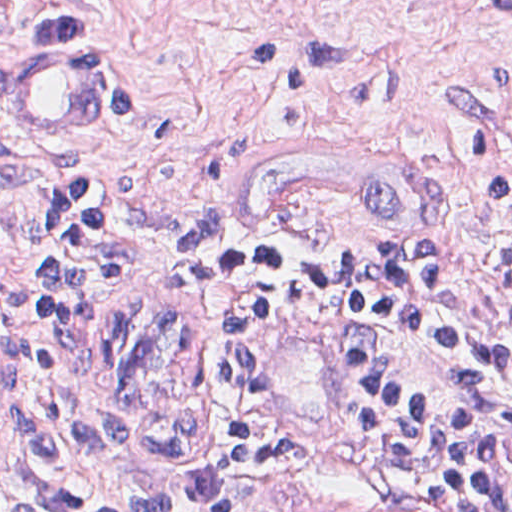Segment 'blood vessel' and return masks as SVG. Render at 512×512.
Masks as SVG:
<instances>
[{
	"label": "blood vessel",
	"mask_w": 512,
	"mask_h": 512,
	"mask_svg": "<svg viewBox=\"0 0 512 512\" xmlns=\"http://www.w3.org/2000/svg\"><path fill=\"white\" fill-rule=\"evenodd\" d=\"M120 59L90 30L60 32L0 75V112L26 140H65L105 119ZM449 193L447 156L392 123L310 117L240 144L224 191L228 221L280 231L318 210L381 221H435ZM23 371L0 351V463L17 443Z\"/></svg>",
	"instance_id": "obj_1"
}]
</instances>
